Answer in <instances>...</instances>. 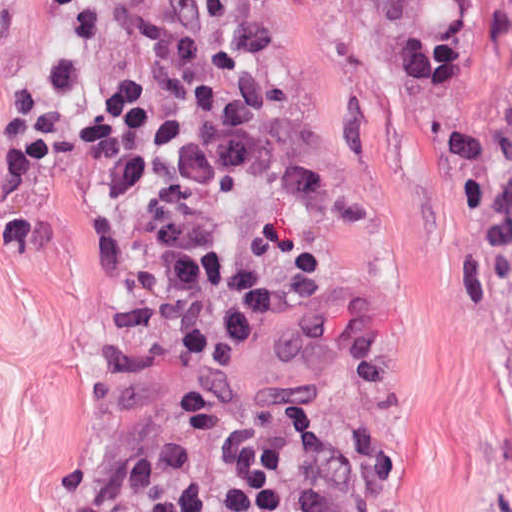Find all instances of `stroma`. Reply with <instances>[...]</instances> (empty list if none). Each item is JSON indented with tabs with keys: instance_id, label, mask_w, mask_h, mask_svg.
Here are the masks:
<instances>
[{
	"instance_id": "1",
	"label": "stroma",
	"mask_w": 512,
	"mask_h": 512,
	"mask_svg": "<svg viewBox=\"0 0 512 512\" xmlns=\"http://www.w3.org/2000/svg\"><path fill=\"white\" fill-rule=\"evenodd\" d=\"M263 1L286 68L278 132L221 176L166 190L228 250L278 155L351 186L366 225L316 219L314 286L374 325L398 386L367 404L311 349L255 332L219 380L238 431L284 408L401 512H512V354L482 215L401 17L392 0ZM52 3L0 0V512H100L119 485L201 452L168 386L113 389L95 361L100 337L165 324L107 254L58 148L31 187L6 184L11 100L41 82Z\"/></svg>"
}]
</instances>
